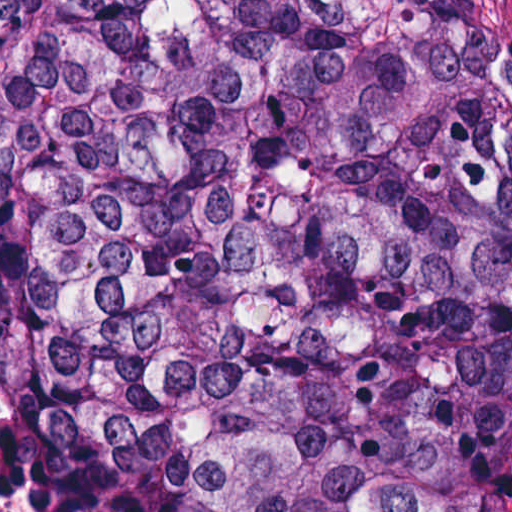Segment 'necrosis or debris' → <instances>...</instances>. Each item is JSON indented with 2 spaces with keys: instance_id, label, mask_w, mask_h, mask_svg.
<instances>
[{
  "instance_id": "necrosis-or-debris-1",
  "label": "necrosis or debris",
  "mask_w": 512,
  "mask_h": 512,
  "mask_svg": "<svg viewBox=\"0 0 512 512\" xmlns=\"http://www.w3.org/2000/svg\"><path fill=\"white\" fill-rule=\"evenodd\" d=\"M0 512H33L22 428L0 396Z\"/></svg>"
}]
</instances>
